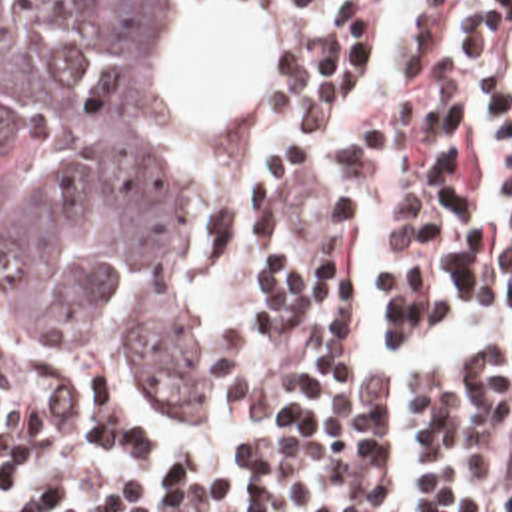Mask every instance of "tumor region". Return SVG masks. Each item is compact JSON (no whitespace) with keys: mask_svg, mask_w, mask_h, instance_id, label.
Instances as JSON below:
<instances>
[{"mask_svg":"<svg viewBox=\"0 0 512 512\" xmlns=\"http://www.w3.org/2000/svg\"><path fill=\"white\" fill-rule=\"evenodd\" d=\"M173 25L175 0H0V255L19 333L103 363L115 329L149 395L219 415L173 181Z\"/></svg>","mask_w":512,"mask_h":512,"instance_id":"e687c5a6","label":"tumor region"}]
</instances>
